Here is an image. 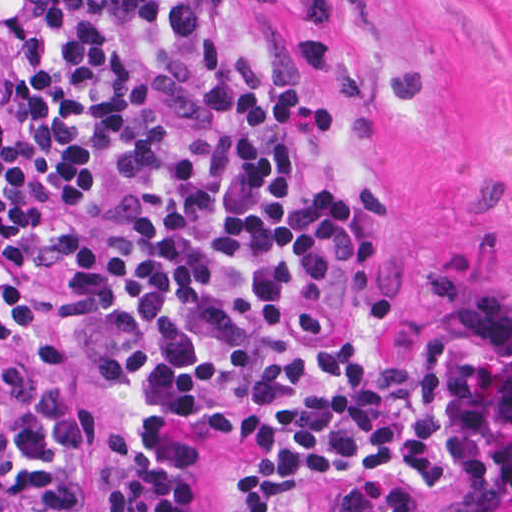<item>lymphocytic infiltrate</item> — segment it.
Segmentation results:
<instances>
[{"label": "lymphocytic infiltrate", "instance_id": "lymphocytic-infiltrate-1", "mask_svg": "<svg viewBox=\"0 0 512 512\" xmlns=\"http://www.w3.org/2000/svg\"><path fill=\"white\" fill-rule=\"evenodd\" d=\"M267 0H0V359L49 364L34 282L125 393L114 512H194L201 422L252 443L238 512H512V290L374 351L341 214L265 110ZM94 429L53 392L0 425V512H83Z\"/></svg>", "mask_w": 512, "mask_h": 512}]
</instances>
